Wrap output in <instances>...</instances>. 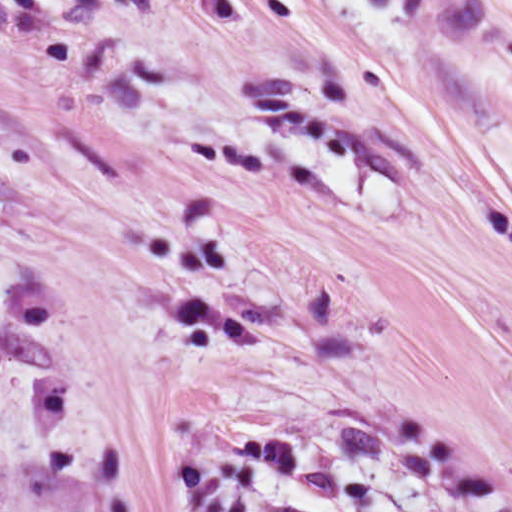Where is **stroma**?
<instances>
[{
	"label": "stroma",
	"mask_w": 512,
	"mask_h": 512,
	"mask_svg": "<svg viewBox=\"0 0 512 512\" xmlns=\"http://www.w3.org/2000/svg\"><path fill=\"white\" fill-rule=\"evenodd\" d=\"M263 512H512V401Z\"/></svg>",
	"instance_id": "obj_1"
}]
</instances>
